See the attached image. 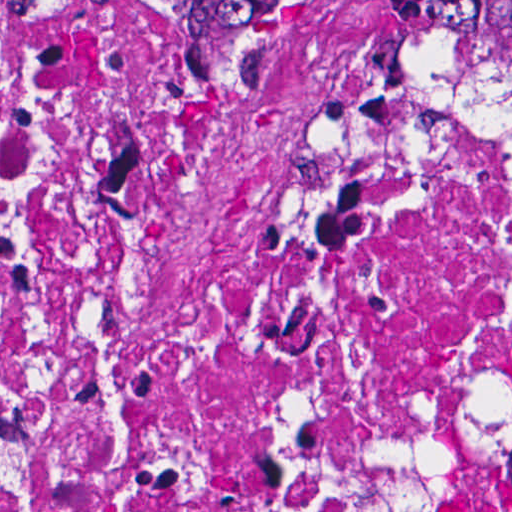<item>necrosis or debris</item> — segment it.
<instances>
[{
    "instance_id": "4bbe7bcc",
    "label": "necrosis or debris",
    "mask_w": 512,
    "mask_h": 512,
    "mask_svg": "<svg viewBox=\"0 0 512 512\" xmlns=\"http://www.w3.org/2000/svg\"><path fill=\"white\" fill-rule=\"evenodd\" d=\"M388 1H1V512H512V99Z\"/></svg>"
}]
</instances>
